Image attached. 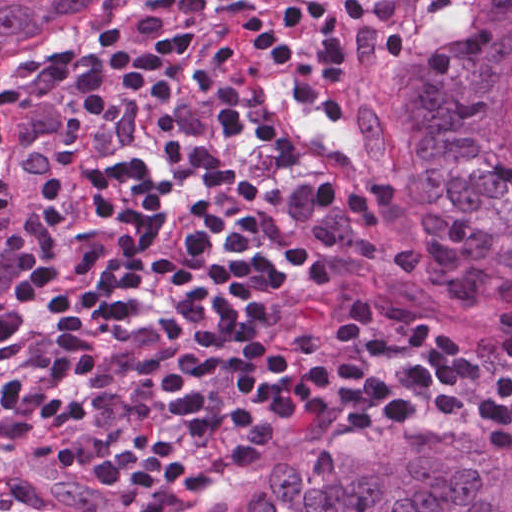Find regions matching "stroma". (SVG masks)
Wrapping results in <instances>:
<instances>
[{
	"mask_svg": "<svg viewBox=\"0 0 512 512\" xmlns=\"http://www.w3.org/2000/svg\"><path fill=\"white\" fill-rule=\"evenodd\" d=\"M463 0H433L414 24L402 27H354L346 48L356 103L374 120L381 167L386 178L402 187L408 168L404 132L406 119L422 97L441 48L450 9ZM204 0H149L108 22L69 50L50 59L0 75V109L30 99L71 79L87 75L130 55L160 38ZM379 185V176L375 178ZM365 189V188H346ZM466 311L463 364L491 373L512 372L508 338L512 310ZM427 416L458 419L457 411ZM416 421H437L415 417ZM457 424L459 422H445ZM359 438L340 432L333 422L315 426L299 437L271 466L255 477H235L200 489L156 512H196L209 500L283 466L342 447Z\"/></svg>",
	"mask_w": 512,
	"mask_h": 512,
	"instance_id": "obj_1",
	"label": "stroma"
}]
</instances>
